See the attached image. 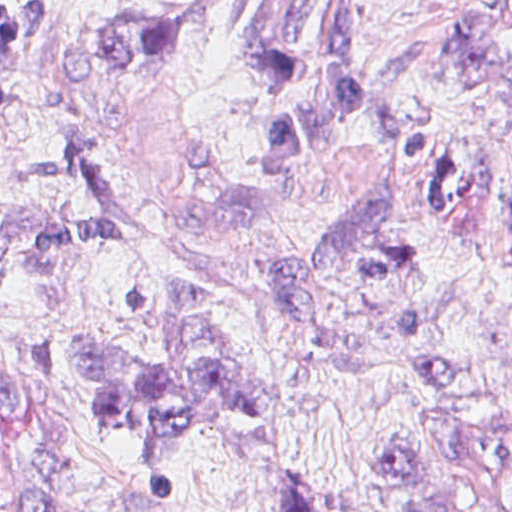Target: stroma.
I'll return each instance as SVG.
<instances>
[{"instance_id":"1","label":"stroma","mask_w":512,"mask_h":512,"mask_svg":"<svg viewBox=\"0 0 512 512\" xmlns=\"http://www.w3.org/2000/svg\"><path fill=\"white\" fill-rule=\"evenodd\" d=\"M0 220L104 209L85 333L169 346L175 289L215 308L252 410L163 485L0 301V512H385L378 449L512 477V27L495 0H371L358 114L280 164L262 84L131 68L159 0H2Z\"/></svg>"}]
</instances>
